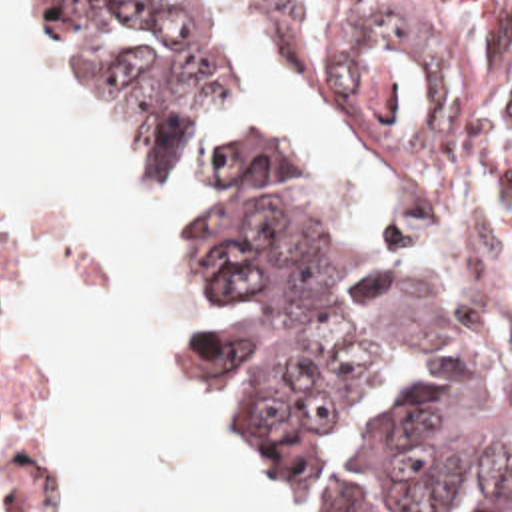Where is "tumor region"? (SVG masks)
Segmentation results:
<instances>
[{"mask_svg":"<svg viewBox=\"0 0 512 512\" xmlns=\"http://www.w3.org/2000/svg\"><path fill=\"white\" fill-rule=\"evenodd\" d=\"M37 32L81 114L111 124L136 180L158 184L222 82L232 32L216 0H37ZM190 246L226 324L182 326L210 419L294 471L340 457L318 421L356 405L384 352H418L412 387L332 512H512V370L432 256L394 222L370 246L302 200L278 140L208 162Z\"/></svg>","mask_w":512,"mask_h":512,"instance_id":"e687c5a6","label":"tumor region"}]
</instances>
